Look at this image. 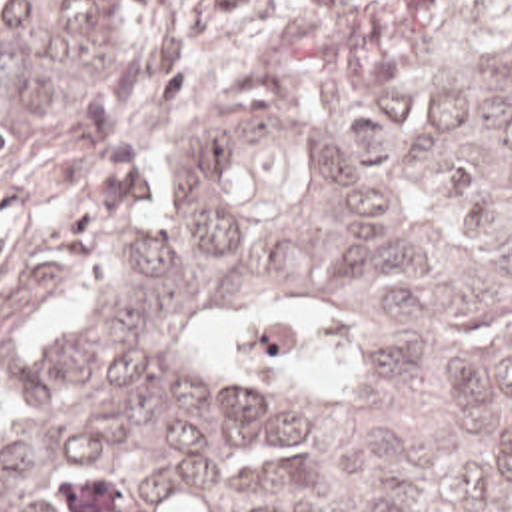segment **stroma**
<instances>
[{"mask_svg": "<svg viewBox=\"0 0 512 512\" xmlns=\"http://www.w3.org/2000/svg\"><path fill=\"white\" fill-rule=\"evenodd\" d=\"M320 0H142V59L0 173V383L54 351L164 227L176 161Z\"/></svg>", "mask_w": 512, "mask_h": 512, "instance_id": "stroma-1", "label": "stroma"}]
</instances>
